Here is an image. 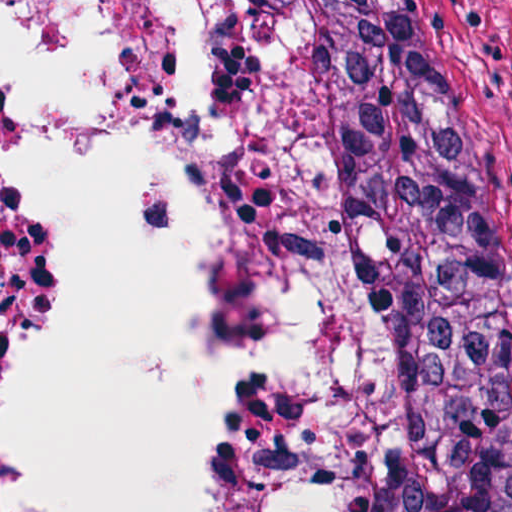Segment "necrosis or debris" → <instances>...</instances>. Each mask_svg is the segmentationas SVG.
Here are the masks:
<instances>
[{
  "label": "necrosis or debris",
  "mask_w": 512,
  "mask_h": 512,
  "mask_svg": "<svg viewBox=\"0 0 512 512\" xmlns=\"http://www.w3.org/2000/svg\"><path fill=\"white\" fill-rule=\"evenodd\" d=\"M47 1L0 0V18ZM126 101L217 282V394L233 456L215 512H377L352 309L227 0H137ZM50 264L46 166L0 57V512H17L10 412Z\"/></svg>",
  "instance_id": "4bbe7bcc"
}]
</instances>
